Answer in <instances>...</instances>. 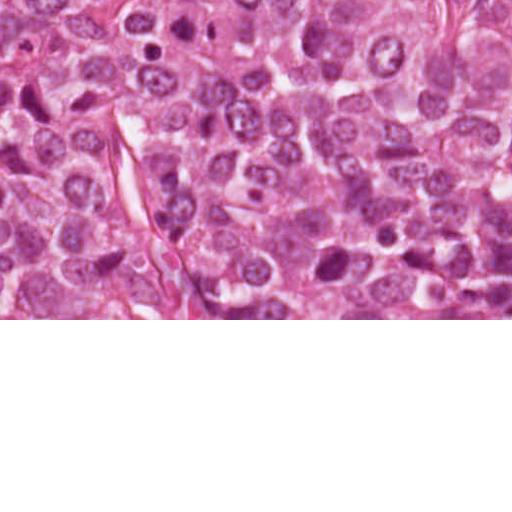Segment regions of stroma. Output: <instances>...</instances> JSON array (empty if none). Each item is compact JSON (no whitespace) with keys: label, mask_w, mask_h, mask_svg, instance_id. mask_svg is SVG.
Instances as JSON below:
<instances>
[{"label":"stroma","mask_w":512,"mask_h":512,"mask_svg":"<svg viewBox=\"0 0 512 512\" xmlns=\"http://www.w3.org/2000/svg\"><path fill=\"white\" fill-rule=\"evenodd\" d=\"M0 320H512V318H244L210 313L45 302L43 319Z\"/></svg>","instance_id":"obj_1"}]
</instances>
